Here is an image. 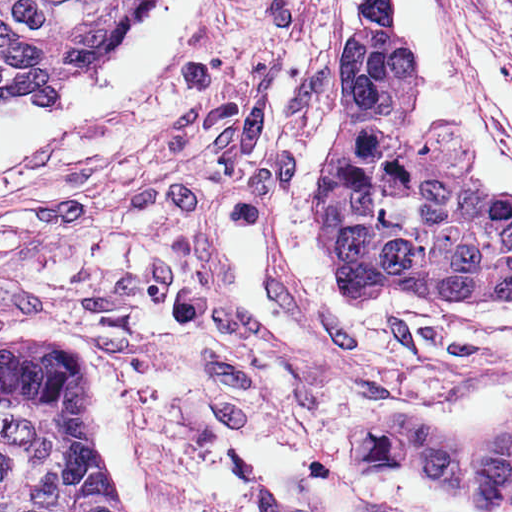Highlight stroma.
Listing matches in <instances>:
<instances>
[{
    "mask_svg": "<svg viewBox=\"0 0 512 512\" xmlns=\"http://www.w3.org/2000/svg\"><path fill=\"white\" fill-rule=\"evenodd\" d=\"M435 1L512 147V0ZM334 3L225 0L116 124L0 191V351L88 357L129 512H368L338 467L348 436L458 509L512 503L410 435L494 448L512 431V299L346 295L315 239L354 46L334 44Z\"/></svg>",
    "mask_w": 512,
    "mask_h": 512,
    "instance_id": "1",
    "label": "stroma"
}]
</instances>
